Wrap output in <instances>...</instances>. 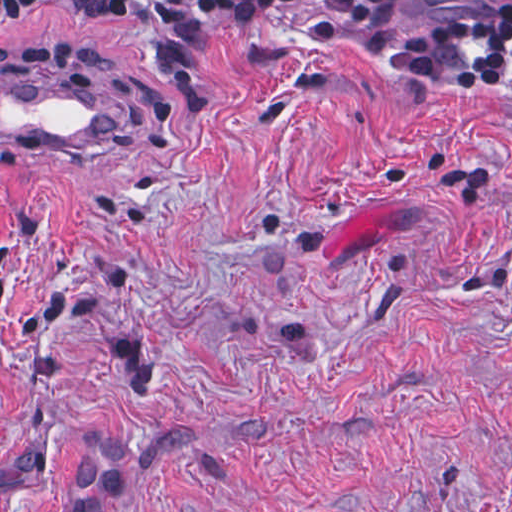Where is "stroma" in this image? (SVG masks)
<instances>
[{"instance_id":"stroma-1","label":"stroma","mask_w":512,"mask_h":512,"mask_svg":"<svg viewBox=\"0 0 512 512\" xmlns=\"http://www.w3.org/2000/svg\"><path fill=\"white\" fill-rule=\"evenodd\" d=\"M199 60L188 103L124 0L0 4V69L117 113L0 153V512H512V88L282 23Z\"/></svg>"}]
</instances>
